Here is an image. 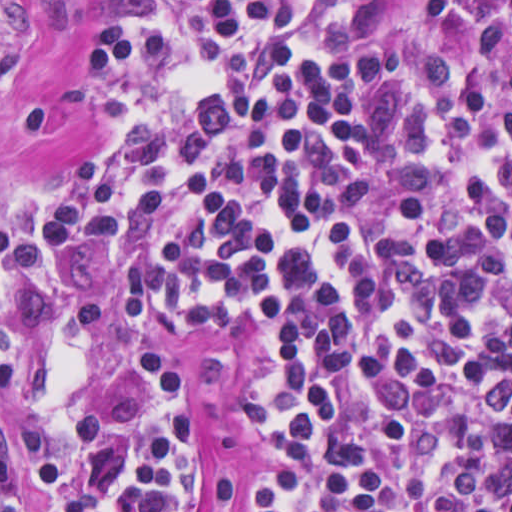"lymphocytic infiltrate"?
I'll use <instances>...</instances> for the list:
<instances>
[{
	"label": "lymphocytic infiltrate",
	"instance_id": "1",
	"mask_svg": "<svg viewBox=\"0 0 512 512\" xmlns=\"http://www.w3.org/2000/svg\"><path fill=\"white\" fill-rule=\"evenodd\" d=\"M88 121L123 135L38 172L39 240L177 338L260 334L232 508L512 512V1H93L87 74L23 124ZM7 203L0 405L39 512H186L187 393L142 355L97 394L101 302L21 260Z\"/></svg>",
	"mask_w": 512,
	"mask_h": 512
}]
</instances>
